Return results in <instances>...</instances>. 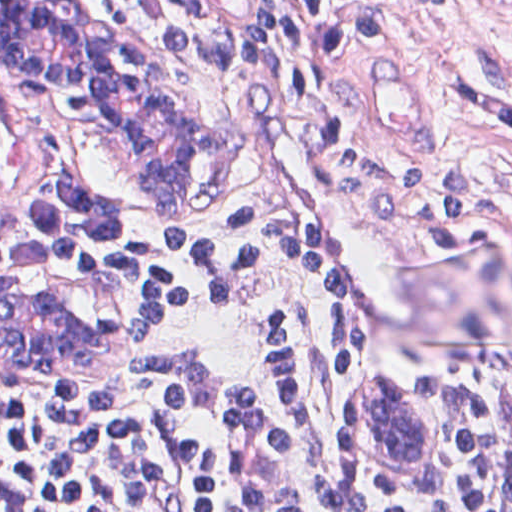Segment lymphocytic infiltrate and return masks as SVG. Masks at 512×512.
<instances>
[{"label": "lymphocytic infiltrate", "instance_id": "obj_1", "mask_svg": "<svg viewBox=\"0 0 512 512\" xmlns=\"http://www.w3.org/2000/svg\"><path fill=\"white\" fill-rule=\"evenodd\" d=\"M261 126L338 146L366 71L427 0H146ZM135 226L72 135L0 96V268L85 261ZM370 324L285 207L186 219L137 250V342L67 418L0 414V512H512V359L424 372L431 502L361 492L337 421Z\"/></svg>", "mask_w": 512, "mask_h": 512}]
</instances>
